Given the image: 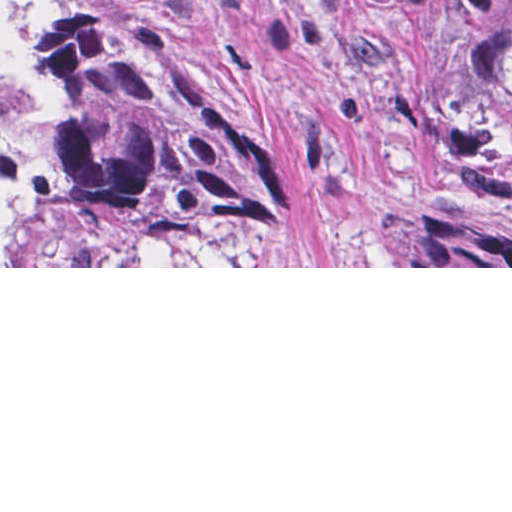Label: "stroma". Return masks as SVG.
<instances>
[{"label":"stroma","instance_id":"stroma-1","mask_svg":"<svg viewBox=\"0 0 512 512\" xmlns=\"http://www.w3.org/2000/svg\"><path fill=\"white\" fill-rule=\"evenodd\" d=\"M130 1L258 126L274 152L269 191L252 212L88 223L0 268H512L388 262L398 209L512 237V198L479 139L403 105L311 0Z\"/></svg>","mask_w":512,"mask_h":512}]
</instances>
